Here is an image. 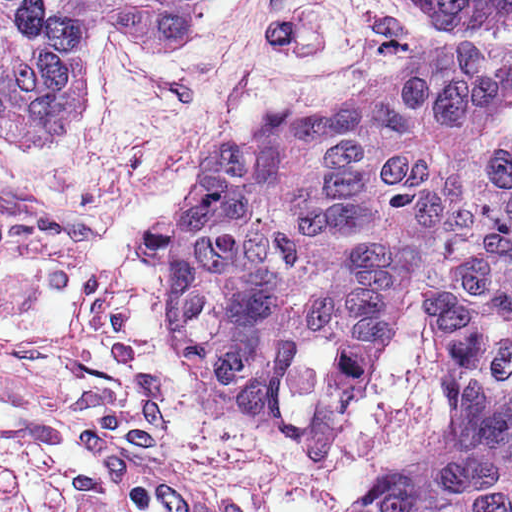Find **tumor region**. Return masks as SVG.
Instances as JSON below:
<instances>
[{"mask_svg":"<svg viewBox=\"0 0 512 512\" xmlns=\"http://www.w3.org/2000/svg\"><path fill=\"white\" fill-rule=\"evenodd\" d=\"M202 0H0V150L53 143L92 35L189 39ZM372 92L223 145L174 196V335L301 461H338L406 299L446 412L353 512H512V0H391Z\"/></svg>","mask_w":512,"mask_h":512,"instance_id":"obj_1","label":"tumor region"}]
</instances>
